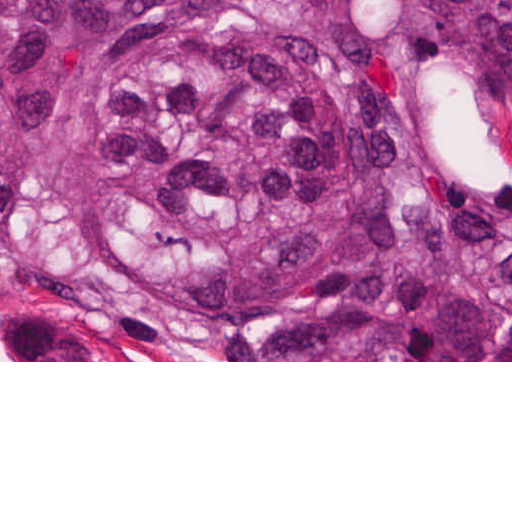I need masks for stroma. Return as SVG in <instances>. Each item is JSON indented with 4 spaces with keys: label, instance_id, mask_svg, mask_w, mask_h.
<instances>
[{
    "label": "stroma",
    "instance_id": "stroma-1",
    "mask_svg": "<svg viewBox=\"0 0 512 512\" xmlns=\"http://www.w3.org/2000/svg\"><path fill=\"white\" fill-rule=\"evenodd\" d=\"M0 362H512V360H215L204 332L199 356L155 358L118 342L95 320H54L30 286L0 274Z\"/></svg>",
    "mask_w": 512,
    "mask_h": 512
}]
</instances>
